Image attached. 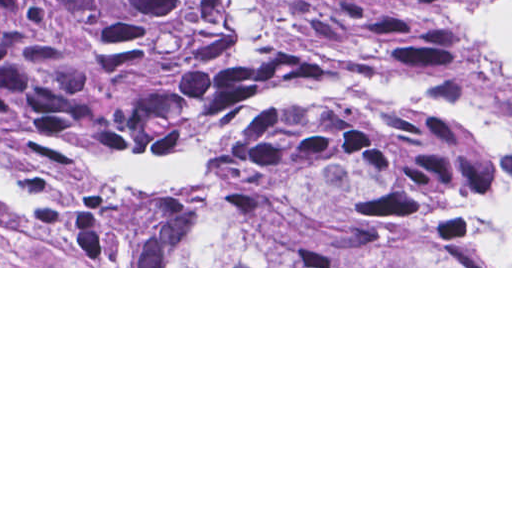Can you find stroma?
Listing matches in <instances>:
<instances>
[{
	"label": "stroma",
	"instance_id": "35a3bbf8",
	"mask_svg": "<svg viewBox=\"0 0 512 512\" xmlns=\"http://www.w3.org/2000/svg\"><path fill=\"white\" fill-rule=\"evenodd\" d=\"M327 252H275L257 240H228L192 266H54L41 243L0 208V268H512V266H323Z\"/></svg>",
	"mask_w": 512,
	"mask_h": 512
}]
</instances>
